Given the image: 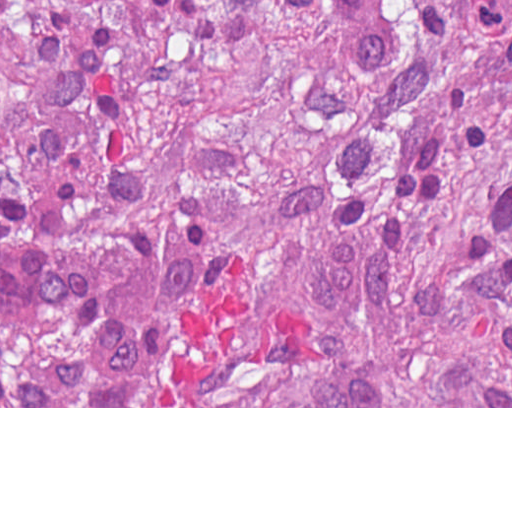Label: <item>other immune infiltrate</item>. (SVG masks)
Returning a JSON list of instances; mask_svg holds the SVG:
<instances>
[{
  "mask_svg": "<svg viewBox=\"0 0 512 512\" xmlns=\"http://www.w3.org/2000/svg\"><path fill=\"white\" fill-rule=\"evenodd\" d=\"M64 244H0V320L47 321L83 308L106 284L92 252Z\"/></svg>",
  "mask_w": 512,
  "mask_h": 512,
  "instance_id": "other-immune-infiltrate-1",
  "label": "other immune infiltrate"
}]
</instances>
